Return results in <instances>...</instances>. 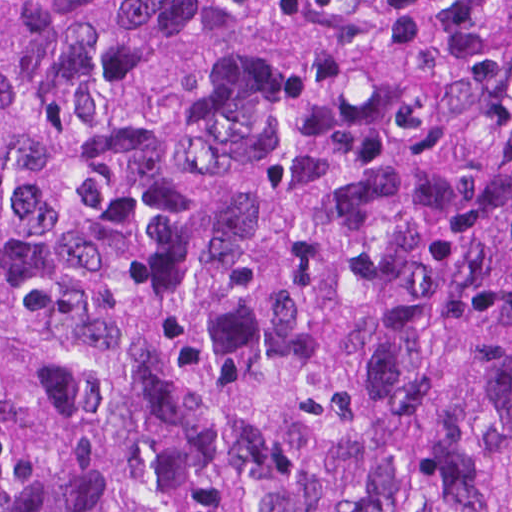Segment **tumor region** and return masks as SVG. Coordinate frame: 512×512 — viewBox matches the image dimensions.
Instances as JSON below:
<instances>
[{
  "mask_svg": "<svg viewBox=\"0 0 512 512\" xmlns=\"http://www.w3.org/2000/svg\"><path fill=\"white\" fill-rule=\"evenodd\" d=\"M0 512H512V0H0Z\"/></svg>",
  "mask_w": 512,
  "mask_h": 512,
  "instance_id": "tumor-region-1",
  "label": "tumor region"
}]
</instances>
